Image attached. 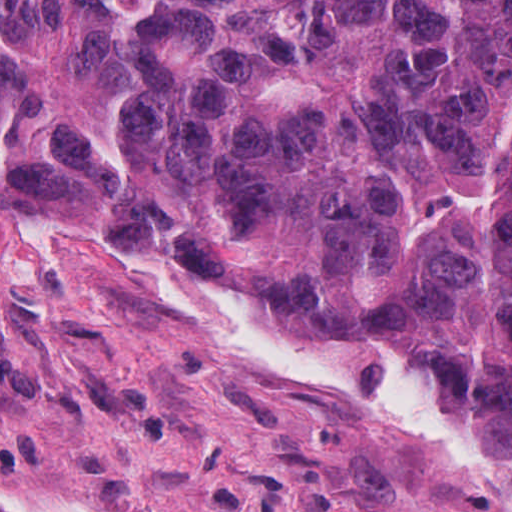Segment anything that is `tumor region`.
Listing matches in <instances>:
<instances>
[{"label": "tumor region", "instance_id": "tumor-region-1", "mask_svg": "<svg viewBox=\"0 0 512 512\" xmlns=\"http://www.w3.org/2000/svg\"><path fill=\"white\" fill-rule=\"evenodd\" d=\"M28 177L512 460V0H0Z\"/></svg>", "mask_w": 512, "mask_h": 512}]
</instances>
